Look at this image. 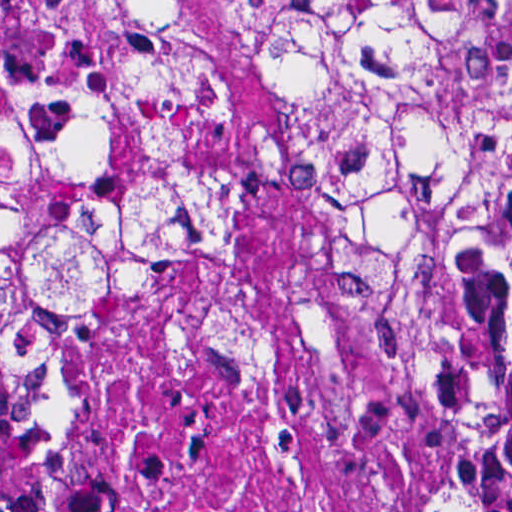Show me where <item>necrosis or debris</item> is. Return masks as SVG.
Segmentation results:
<instances>
[{
	"label": "necrosis or debris",
	"mask_w": 512,
	"mask_h": 512,
	"mask_svg": "<svg viewBox=\"0 0 512 512\" xmlns=\"http://www.w3.org/2000/svg\"><path fill=\"white\" fill-rule=\"evenodd\" d=\"M82 417L16 512H409L436 428L321 293L299 190L248 199L232 269L176 280L73 346Z\"/></svg>",
	"instance_id": "obj_1"
}]
</instances>
